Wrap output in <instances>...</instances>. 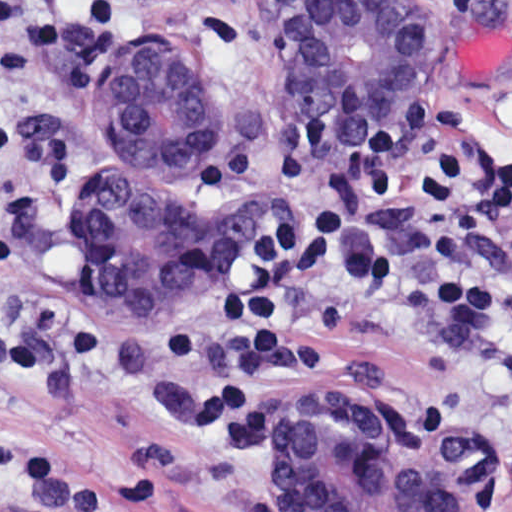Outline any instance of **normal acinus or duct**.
Returning a JSON list of instances; mask_svg holds the SVG:
<instances>
[{
	"instance_id": "1",
	"label": "normal acinus or duct",
	"mask_w": 512,
	"mask_h": 512,
	"mask_svg": "<svg viewBox=\"0 0 512 512\" xmlns=\"http://www.w3.org/2000/svg\"><path fill=\"white\" fill-rule=\"evenodd\" d=\"M375 2L409 3L289 8L281 74L298 114L367 132L383 112L421 43V19ZM226 117L227 37L219 18L191 9L145 18V35L97 87L67 216L128 320H178L201 275L270 245L278 208L203 190L198 171ZM275 488L287 512H488L484 465L364 390L293 400L275 434Z\"/></svg>"
}]
</instances>
